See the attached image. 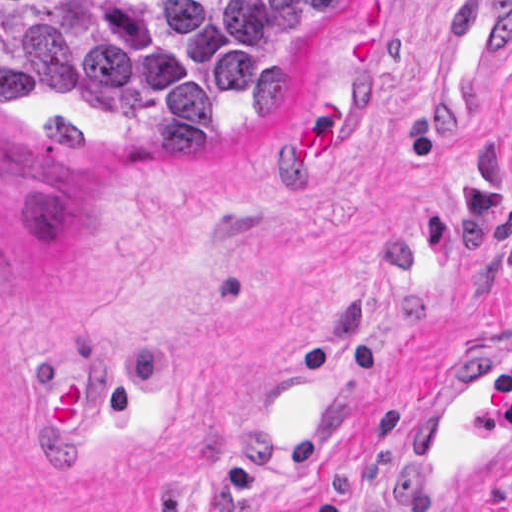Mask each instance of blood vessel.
I'll use <instances>...</instances> for the list:
<instances>
[{
    "instance_id": "8fb6f2fc",
    "label": "blood vessel",
    "mask_w": 512,
    "mask_h": 512,
    "mask_svg": "<svg viewBox=\"0 0 512 512\" xmlns=\"http://www.w3.org/2000/svg\"><path fill=\"white\" fill-rule=\"evenodd\" d=\"M512 21V0H479L441 40L422 89L424 133L469 129L486 65ZM313 359V358H312ZM260 385L244 400V461L286 467L318 438L331 408L325 367ZM92 422L87 355L48 366L41 401V455H79ZM512 482V347L459 361L422 381L400 451V509L475 512Z\"/></svg>"
}]
</instances>
